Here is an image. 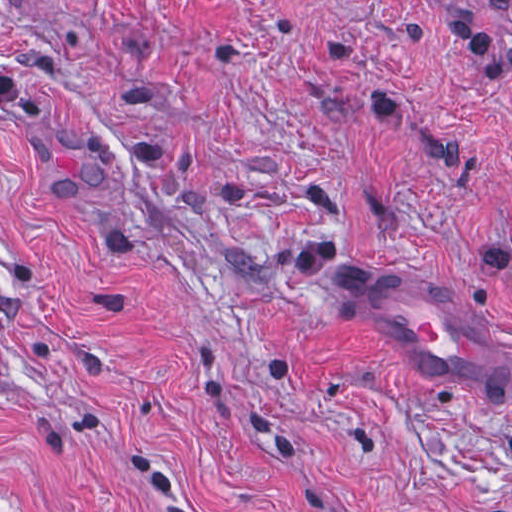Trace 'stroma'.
<instances>
[{"instance_id": "1", "label": "stroma", "mask_w": 512, "mask_h": 512, "mask_svg": "<svg viewBox=\"0 0 512 512\" xmlns=\"http://www.w3.org/2000/svg\"><path fill=\"white\" fill-rule=\"evenodd\" d=\"M355 257L512 341V0H0V512H512Z\"/></svg>"}]
</instances>
